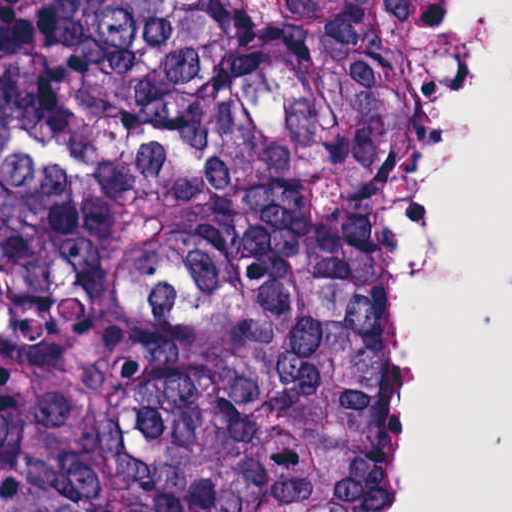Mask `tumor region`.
<instances>
[{
    "label": "tumor region",
    "mask_w": 512,
    "mask_h": 512,
    "mask_svg": "<svg viewBox=\"0 0 512 512\" xmlns=\"http://www.w3.org/2000/svg\"><path fill=\"white\" fill-rule=\"evenodd\" d=\"M435 0H0V512H385L380 178Z\"/></svg>",
    "instance_id": "obj_1"
}]
</instances>
